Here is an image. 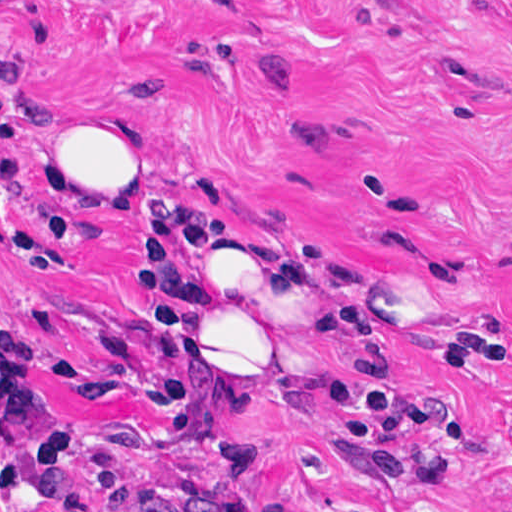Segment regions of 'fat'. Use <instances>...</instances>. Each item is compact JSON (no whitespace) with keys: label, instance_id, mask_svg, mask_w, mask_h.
Masks as SVG:
<instances>
[{"label":"fat","instance_id":"1","mask_svg":"<svg viewBox=\"0 0 512 512\" xmlns=\"http://www.w3.org/2000/svg\"><path fill=\"white\" fill-rule=\"evenodd\" d=\"M163 155L148 116L61 106L46 135V199L138 179ZM201 285L231 392L249 398L288 374L335 410L343 373L302 217L280 200L219 212Z\"/></svg>","mask_w":512,"mask_h":512}]
</instances>
